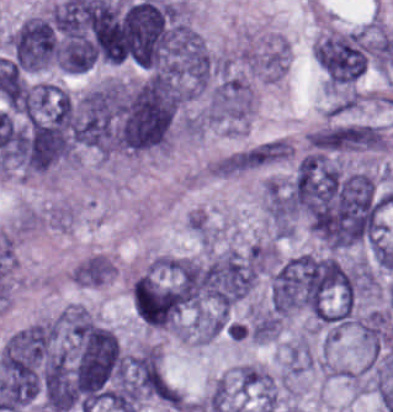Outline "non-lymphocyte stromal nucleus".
<instances>
[{
    "mask_svg": "<svg viewBox=\"0 0 393 412\" xmlns=\"http://www.w3.org/2000/svg\"><path fill=\"white\" fill-rule=\"evenodd\" d=\"M262 207L279 236H288L293 232L296 207L289 180L268 177L262 185Z\"/></svg>",
    "mask_w": 393,
    "mask_h": 412,
    "instance_id": "non-lymphocyte-stromal-nucleus-1",
    "label": "non-lymphocyte stromal nucleus"
}]
</instances>
